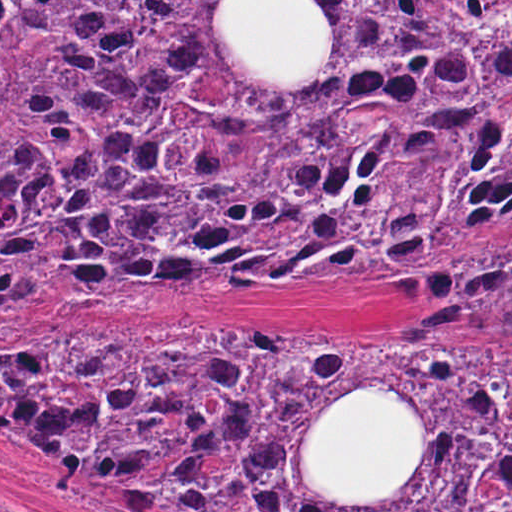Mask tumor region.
<instances>
[{
    "mask_svg": "<svg viewBox=\"0 0 512 512\" xmlns=\"http://www.w3.org/2000/svg\"><path fill=\"white\" fill-rule=\"evenodd\" d=\"M231 2L0 1V329L512 275V1H306L328 26L311 75L256 73L219 30ZM424 326L511 340L512 281ZM0 435L178 512H512V344L348 326L0 344Z\"/></svg>",
    "mask_w": 512,
    "mask_h": 512,
    "instance_id": "tumor-region-1",
    "label": "tumor region"
}]
</instances>
